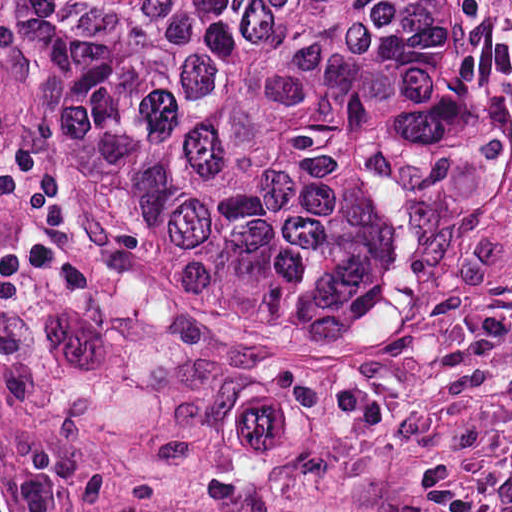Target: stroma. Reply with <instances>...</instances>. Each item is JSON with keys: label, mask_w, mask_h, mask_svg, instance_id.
<instances>
[{"label": "stroma", "mask_w": 512, "mask_h": 512, "mask_svg": "<svg viewBox=\"0 0 512 512\" xmlns=\"http://www.w3.org/2000/svg\"><path fill=\"white\" fill-rule=\"evenodd\" d=\"M0 512H231L0 437Z\"/></svg>", "instance_id": "stroma-1"}]
</instances>
